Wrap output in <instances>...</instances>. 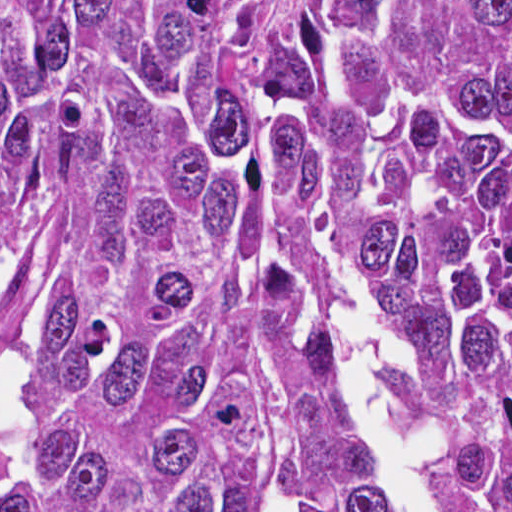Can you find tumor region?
<instances>
[{
    "label": "tumor region",
    "instance_id": "1",
    "mask_svg": "<svg viewBox=\"0 0 512 512\" xmlns=\"http://www.w3.org/2000/svg\"><path fill=\"white\" fill-rule=\"evenodd\" d=\"M347 277L512 512V0H1V512H394Z\"/></svg>",
    "mask_w": 512,
    "mask_h": 512
}]
</instances>
